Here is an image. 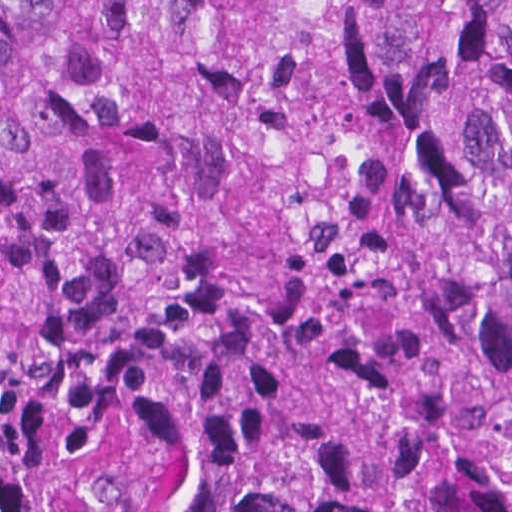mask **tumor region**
Wrapping results in <instances>:
<instances>
[{"instance_id":"1","label":"tumor region","mask_w":512,"mask_h":512,"mask_svg":"<svg viewBox=\"0 0 512 512\" xmlns=\"http://www.w3.org/2000/svg\"><path fill=\"white\" fill-rule=\"evenodd\" d=\"M0 512H512V0H0Z\"/></svg>"}]
</instances>
